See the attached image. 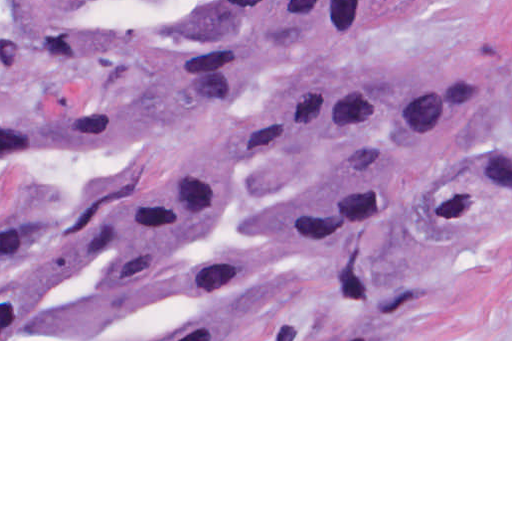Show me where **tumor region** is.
Returning <instances> with one entry per match:
<instances>
[{"mask_svg": "<svg viewBox=\"0 0 512 512\" xmlns=\"http://www.w3.org/2000/svg\"><path fill=\"white\" fill-rule=\"evenodd\" d=\"M400 1L0 0L2 59L101 77L82 102L0 124V162L131 150L229 106L291 56L358 40ZM209 126L217 134L161 150L103 251L0 263V339H383L414 298L408 279L174 260L239 199V162H512L495 98L338 92L295 102L236 142ZM408 189L384 176L306 192L269 240L289 259L348 255Z\"/></svg>", "mask_w": 512, "mask_h": 512, "instance_id": "tumor-region-1", "label": "tumor region"}]
</instances>
